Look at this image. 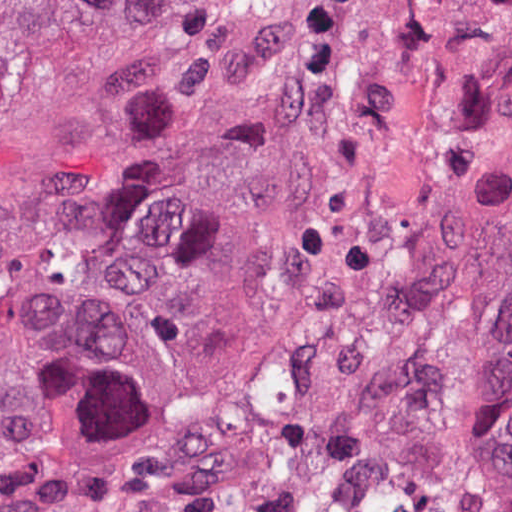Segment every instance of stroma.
Wrapping results in <instances>:
<instances>
[{"mask_svg": "<svg viewBox=\"0 0 512 512\" xmlns=\"http://www.w3.org/2000/svg\"><path fill=\"white\" fill-rule=\"evenodd\" d=\"M0 512H512V0L28 17Z\"/></svg>", "mask_w": 512, "mask_h": 512, "instance_id": "obj_1", "label": "stroma"}]
</instances>
